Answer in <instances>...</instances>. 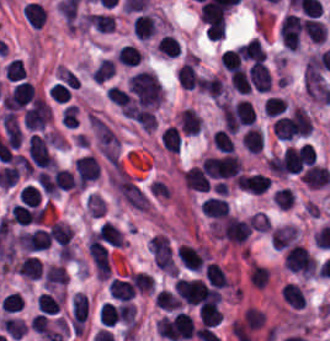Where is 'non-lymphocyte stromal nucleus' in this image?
Returning a JSON list of instances; mask_svg holds the SVG:
<instances>
[{
    "mask_svg": "<svg viewBox=\"0 0 330 341\" xmlns=\"http://www.w3.org/2000/svg\"><path fill=\"white\" fill-rule=\"evenodd\" d=\"M109 180L117 194L125 202L137 210H147V196L126 171L115 165Z\"/></svg>",
    "mask_w": 330,
    "mask_h": 341,
    "instance_id": "dd21d789",
    "label": "non-lymphocyte stromal nucleus"
},
{
    "mask_svg": "<svg viewBox=\"0 0 330 341\" xmlns=\"http://www.w3.org/2000/svg\"><path fill=\"white\" fill-rule=\"evenodd\" d=\"M88 124L100 153L105 158H116L120 143L111 127L90 113Z\"/></svg>",
    "mask_w": 330,
    "mask_h": 341,
    "instance_id": "a72fc3eb",
    "label": "non-lymphocyte stromal nucleus"
},
{
    "mask_svg": "<svg viewBox=\"0 0 330 341\" xmlns=\"http://www.w3.org/2000/svg\"><path fill=\"white\" fill-rule=\"evenodd\" d=\"M253 225L249 221L229 217L220 228L218 239L234 245H241L252 232Z\"/></svg>",
    "mask_w": 330,
    "mask_h": 341,
    "instance_id": "3746e769",
    "label": "non-lymphocyte stromal nucleus"
}]
</instances>
